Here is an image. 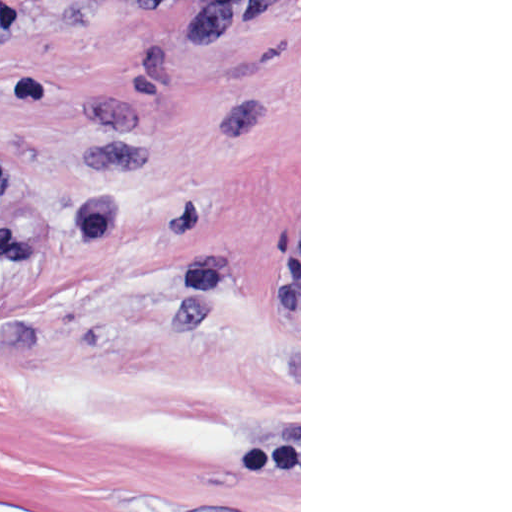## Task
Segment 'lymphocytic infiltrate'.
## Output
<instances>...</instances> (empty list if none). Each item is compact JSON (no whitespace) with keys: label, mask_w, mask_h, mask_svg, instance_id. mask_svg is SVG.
Instances as JSON below:
<instances>
[{"label":"lymphocytic infiltrate","mask_w":512,"mask_h":512,"mask_svg":"<svg viewBox=\"0 0 512 512\" xmlns=\"http://www.w3.org/2000/svg\"><path fill=\"white\" fill-rule=\"evenodd\" d=\"M57 8L88 10L111 0H36ZM157 20L195 5L199 33L206 46H225L244 23L257 15L266 0H135ZM22 178L15 167L0 157V210L20 203ZM124 217V201L116 196L83 198L48 205L24 217L0 218V277L16 272L32 253V239L50 231L77 242H103Z\"/></svg>","instance_id":"lymphocytic-infiltrate-1"}]
</instances>
